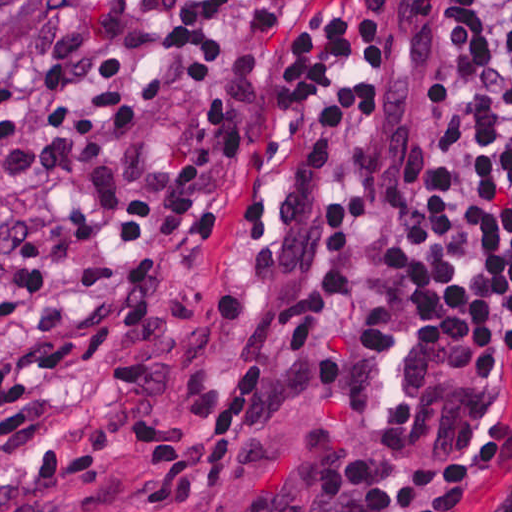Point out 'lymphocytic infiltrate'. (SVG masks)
<instances>
[{
  "label": "lymphocytic infiltrate",
  "instance_id": "lymphocytic-infiltrate-1",
  "mask_svg": "<svg viewBox=\"0 0 512 512\" xmlns=\"http://www.w3.org/2000/svg\"><path fill=\"white\" fill-rule=\"evenodd\" d=\"M429 159L413 213L341 217L329 200L289 308L286 379L261 417L338 416L349 512H512L493 464H423L364 432L367 339L412 314L489 370L512 353V0H448L426 70Z\"/></svg>",
  "mask_w": 512,
  "mask_h": 512
}]
</instances>
